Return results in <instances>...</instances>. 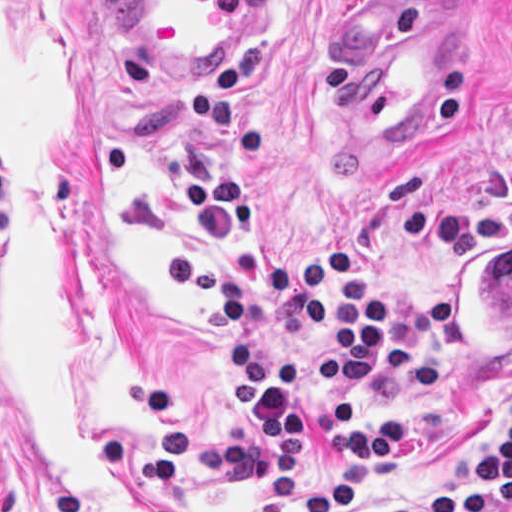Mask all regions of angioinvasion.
Segmentation results:
<instances>
[{
    "label": "angioinvasion",
    "instance_id": "e142278d",
    "mask_svg": "<svg viewBox=\"0 0 512 512\" xmlns=\"http://www.w3.org/2000/svg\"><path fill=\"white\" fill-rule=\"evenodd\" d=\"M450 364L465 382L492 378L512 357V232L461 242L445 278Z\"/></svg>",
    "mask_w": 512,
    "mask_h": 512
}]
</instances>
